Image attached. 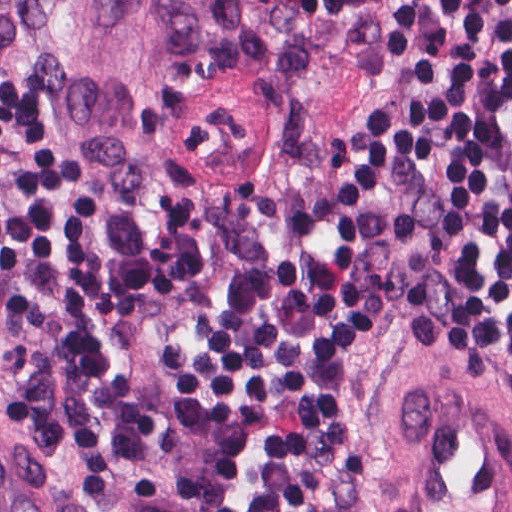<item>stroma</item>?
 <instances>
[{
  "label": "stroma",
  "instance_id": "obj_1",
  "mask_svg": "<svg viewBox=\"0 0 512 512\" xmlns=\"http://www.w3.org/2000/svg\"><path fill=\"white\" fill-rule=\"evenodd\" d=\"M0 88L73 121L99 217L91 347L163 418V447L92 505L67 452L10 436L47 320L0 284V510L266 512L254 448L194 402L197 361L395 149L397 0H0ZM413 343L351 371L340 512H512V371Z\"/></svg>",
  "mask_w": 512,
  "mask_h": 512
}]
</instances>
